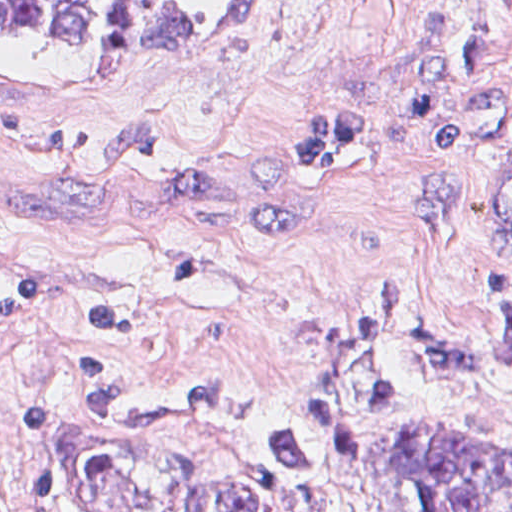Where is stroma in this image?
<instances>
[{
  "instance_id": "stroma-1",
  "label": "stroma",
  "mask_w": 512,
  "mask_h": 512,
  "mask_svg": "<svg viewBox=\"0 0 512 512\" xmlns=\"http://www.w3.org/2000/svg\"><path fill=\"white\" fill-rule=\"evenodd\" d=\"M486 17L484 0H269L192 41L0 33V512H28L33 392L60 412L67 512H146L175 479H221L230 436L388 271L464 341L495 337L512 252L412 239L437 164L418 105L386 114L335 195L299 189L286 157L318 100L387 85ZM402 417L512 443V386L415 395L367 422L351 469L290 494L391 512L372 441Z\"/></svg>"
}]
</instances>
